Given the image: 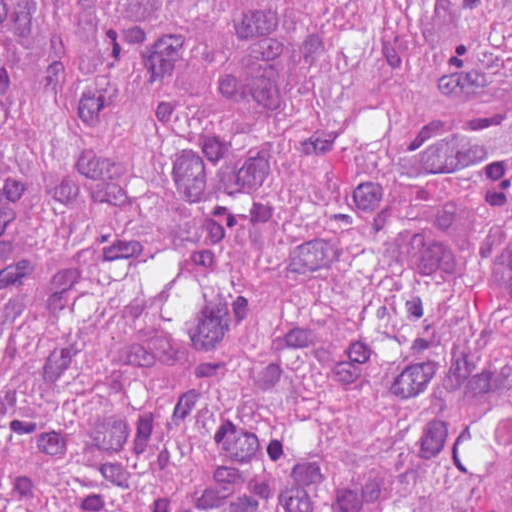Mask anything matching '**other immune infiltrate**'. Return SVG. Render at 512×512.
<instances>
[{
    "label": "other immune infiltrate",
    "mask_w": 512,
    "mask_h": 512,
    "mask_svg": "<svg viewBox=\"0 0 512 512\" xmlns=\"http://www.w3.org/2000/svg\"><path fill=\"white\" fill-rule=\"evenodd\" d=\"M315 0H230L208 61L212 98L232 115H259Z\"/></svg>",
    "instance_id": "bc1004c8"
}]
</instances>
